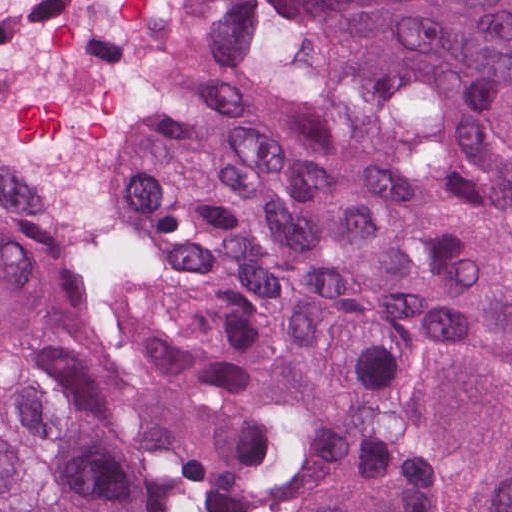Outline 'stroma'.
Here are the masks:
<instances>
[{
  "label": "stroma",
  "instance_id": "35a3bbf8",
  "mask_svg": "<svg viewBox=\"0 0 512 512\" xmlns=\"http://www.w3.org/2000/svg\"><path fill=\"white\" fill-rule=\"evenodd\" d=\"M224 1L211 0L207 21ZM153 260L125 227L115 265L97 295L67 301L55 268V225L44 194V271L71 308L117 353L115 322L136 281ZM170 432L202 512H300L320 482V460L304 448L250 465H221L200 456Z\"/></svg>",
  "mask_w": 512,
  "mask_h": 512
}]
</instances>
